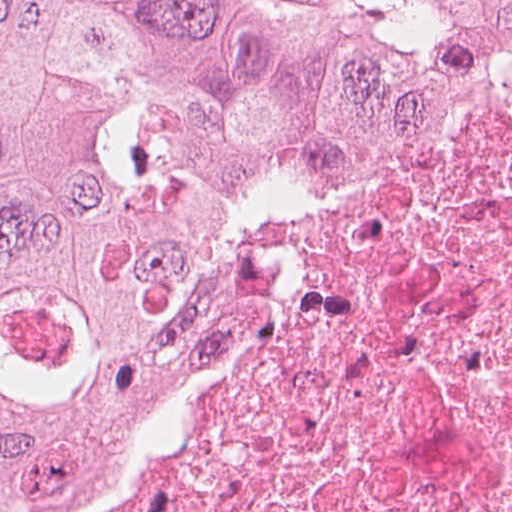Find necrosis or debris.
I'll list each match as a JSON object with an SVG mask.
<instances>
[{"label": "necrosis or debris", "instance_id": "necrosis-or-debris-1", "mask_svg": "<svg viewBox=\"0 0 512 512\" xmlns=\"http://www.w3.org/2000/svg\"><path fill=\"white\" fill-rule=\"evenodd\" d=\"M193 401L60 512H512V54L264 176Z\"/></svg>", "mask_w": 512, "mask_h": 512}]
</instances>
